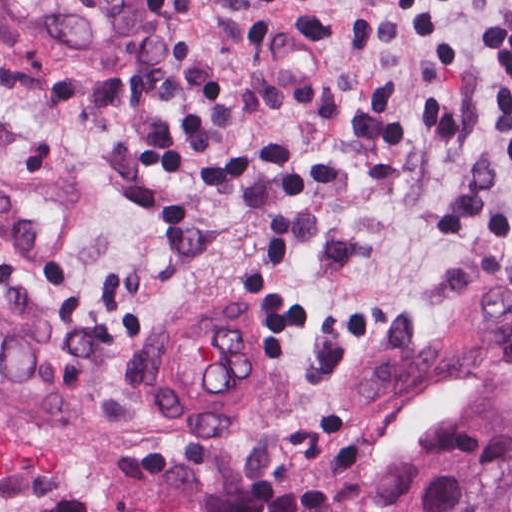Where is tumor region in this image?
<instances>
[{"mask_svg":"<svg viewBox=\"0 0 512 512\" xmlns=\"http://www.w3.org/2000/svg\"><path fill=\"white\" fill-rule=\"evenodd\" d=\"M472 308L482 336L512 356V244L483 275Z\"/></svg>","mask_w":512,"mask_h":512,"instance_id":"1","label":"tumor region"}]
</instances>
